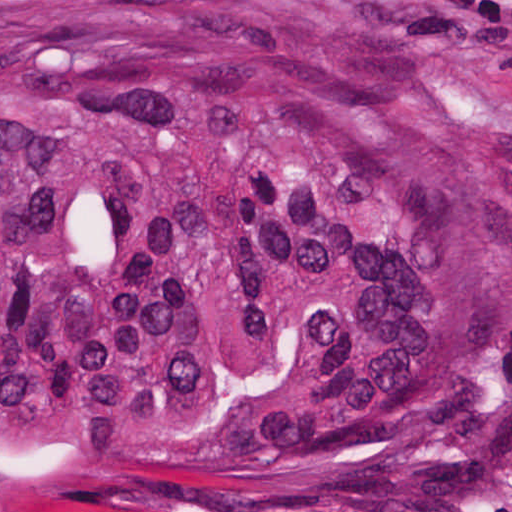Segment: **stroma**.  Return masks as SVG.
I'll return each instance as SVG.
<instances>
[{
	"mask_svg": "<svg viewBox=\"0 0 512 512\" xmlns=\"http://www.w3.org/2000/svg\"><path fill=\"white\" fill-rule=\"evenodd\" d=\"M412 63L506 145L512 166V0H277ZM29 512H512V404L472 448L417 473L294 498H149Z\"/></svg>",
	"mask_w": 512,
	"mask_h": 512,
	"instance_id": "35a3bbf8",
	"label": "stroma"
}]
</instances>
